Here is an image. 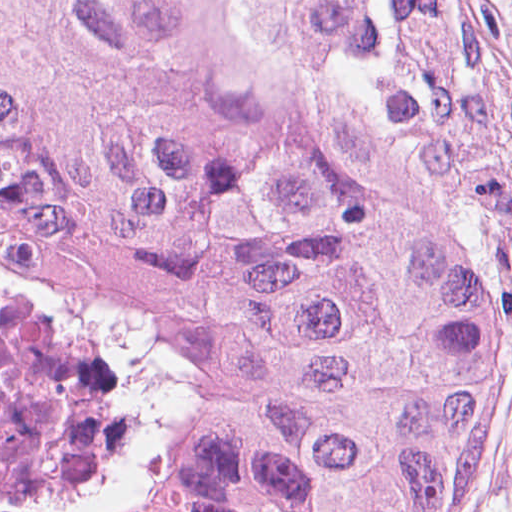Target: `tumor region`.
Returning <instances> with one entry per match:
<instances>
[{"instance_id": "obj_1", "label": "tumor region", "mask_w": 512, "mask_h": 512, "mask_svg": "<svg viewBox=\"0 0 512 512\" xmlns=\"http://www.w3.org/2000/svg\"><path fill=\"white\" fill-rule=\"evenodd\" d=\"M0 243L116 340L186 512H450L512 390L482 0H0Z\"/></svg>"}]
</instances>
